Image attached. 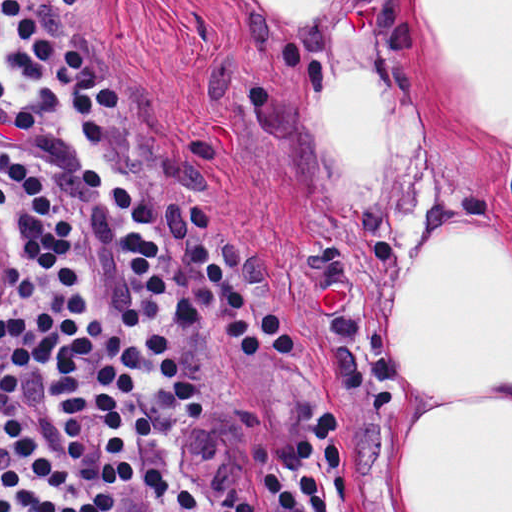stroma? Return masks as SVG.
<instances>
[{"label": "stroma", "instance_id": "obj_1", "mask_svg": "<svg viewBox=\"0 0 512 512\" xmlns=\"http://www.w3.org/2000/svg\"><path fill=\"white\" fill-rule=\"evenodd\" d=\"M116 79L127 110L99 112L102 141L86 144L73 94L37 128L0 104V143L53 187L73 221L80 271L108 337L142 349L168 336L204 400L190 424L153 373L140 378L152 433L138 439L150 512H180L186 485L203 508L252 494L264 458L316 412L337 415L347 504L328 512H408L402 450L412 423L396 391L400 286L432 238L462 218L512 254V143L482 130L446 92L408 27L401 76L416 118L422 191L409 224L361 235L335 208L310 159L308 91L260 31L250 0H30ZM25 49L0 12V78L15 99L32 85L9 59ZM96 168L157 217L142 233L167 295L131 267L129 230ZM204 234L252 304H272L292 349L245 355L223 334L219 296L191 257ZM37 268L44 260L23 240ZM18 309H14L16 311ZM262 512H274L268 501Z\"/></svg>", "mask_w": 512, "mask_h": 512}]
</instances>
